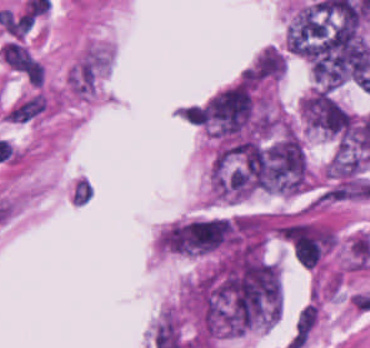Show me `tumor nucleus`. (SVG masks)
<instances>
[{
	"label": "tumor nucleus",
	"mask_w": 370,
	"mask_h": 348,
	"mask_svg": "<svg viewBox=\"0 0 370 348\" xmlns=\"http://www.w3.org/2000/svg\"><path fill=\"white\" fill-rule=\"evenodd\" d=\"M266 140L231 141L216 150L210 174L213 199L236 200L261 190Z\"/></svg>",
	"instance_id": "obj_1"
},
{
	"label": "tumor nucleus",
	"mask_w": 370,
	"mask_h": 348,
	"mask_svg": "<svg viewBox=\"0 0 370 348\" xmlns=\"http://www.w3.org/2000/svg\"><path fill=\"white\" fill-rule=\"evenodd\" d=\"M303 124L315 132L337 136L347 129L348 110L331 88L311 87L301 98Z\"/></svg>",
	"instance_id": "obj_2"
},
{
	"label": "tumor nucleus",
	"mask_w": 370,
	"mask_h": 348,
	"mask_svg": "<svg viewBox=\"0 0 370 348\" xmlns=\"http://www.w3.org/2000/svg\"><path fill=\"white\" fill-rule=\"evenodd\" d=\"M233 222L227 217H207L180 223V251L207 255L227 244Z\"/></svg>",
	"instance_id": "obj_3"
},
{
	"label": "tumor nucleus",
	"mask_w": 370,
	"mask_h": 348,
	"mask_svg": "<svg viewBox=\"0 0 370 348\" xmlns=\"http://www.w3.org/2000/svg\"><path fill=\"white\" fill-rule=\"evenodd\" d=\"M286 69V54L276 45H268L243 71L248 80L267 84L277 80Z\"/></svg>",
	"instance_id": "obj_4"
}]
</instances>
